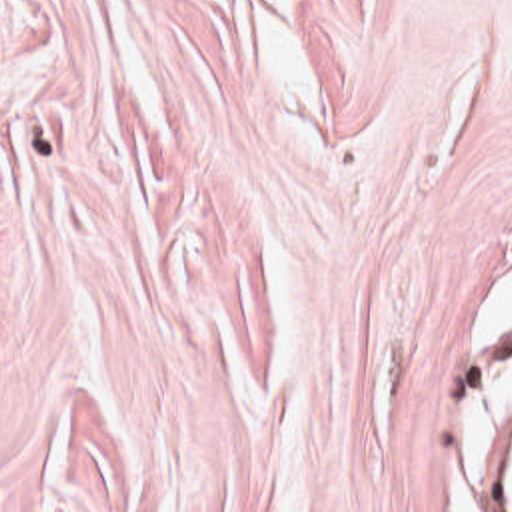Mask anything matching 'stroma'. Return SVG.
<instances>
[{
	"instance_id": "1",
	"label": "stroma",
	"mask_w": 512,
	"mask_h": 512,
	"mask_svg": "<svg viewBox=\"0 0 512 512\" xmlns=\"http://www.w3.org/2000/svg\"><path fill=\"white\" fill-rule=\"evenodd\" d=\"M510 279L512 0H0V512H500Z\"/></svg>"
}]
</instances>
